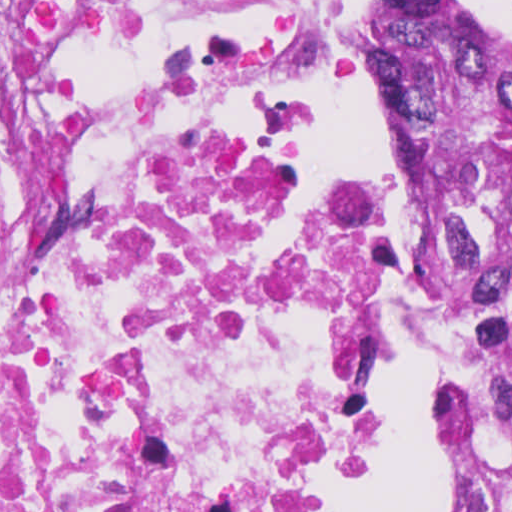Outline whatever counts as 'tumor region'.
Listing matches in <instances>:
<instances>
[{"label": "tumor region", "instance_id": "1", "mask_svg": "<svg viewBox=\"0 0 512 512\" xmlns=\"http://www.w3.org/2000/svg\"><path fill=\"white\" fill-rule=\"evenodd\" d=\"M381 62L454 332L440 512H512V57L468 0H373Z\"/></svg>", "mask_w": 512, "mask_h": 512}]
</instances>
